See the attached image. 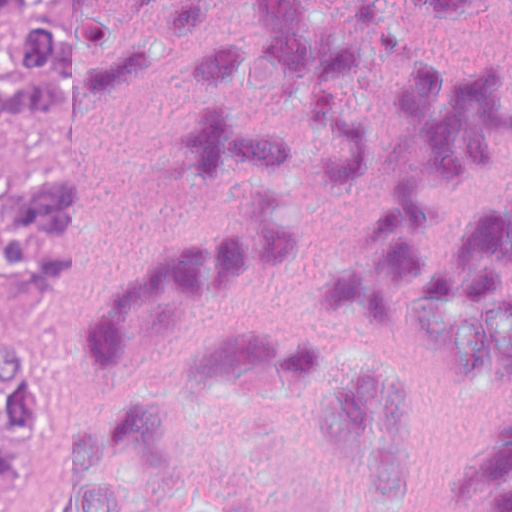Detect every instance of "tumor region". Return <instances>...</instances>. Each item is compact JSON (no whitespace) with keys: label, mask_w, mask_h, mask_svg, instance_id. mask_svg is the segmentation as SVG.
Returning <instances> with one entry per match:
<instances>
[{"label":"tumor region","mask_w":512,"mask_h":512,"mask_svg":"<svg viewBox=\"0 0 512 512\" xmlns=\"http://www.w3.org/2000/svg\"><path fill=\"white\" fill-rule=\"evenodd\" d=\"M20 0H0V18ZM37 0L0 36V270L17 293L62 284L79 239L77 185L47 84V6ZM48 424L25 343L0 336V512Z\"/></svg>","instance_id":"tumor-region-1"}]
</instances>
